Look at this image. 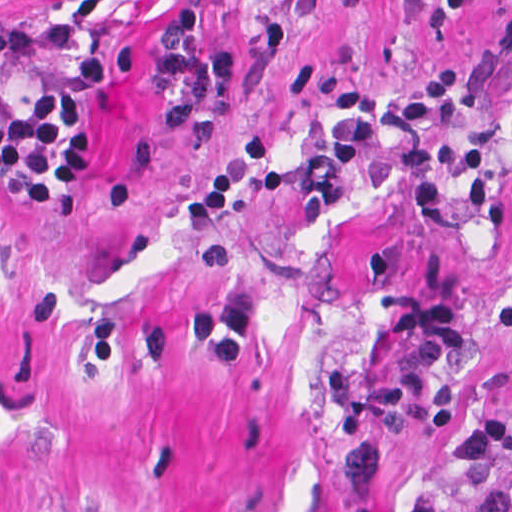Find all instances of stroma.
<instances>
[{"label": "stroma", "instance_id": "obj_1", "mask_svg": "<svg viewBox=\"0 0 512 512\" xmlns=\"http://www.w3.org/2000/svg\"><path fill=\"white\" fill-rule=\"evenodd\" d=\"M205 15L234 93L170 132L140 56L92 92L71 67ZM456 73L434 143L501 135L506 226L406 223L384 132L328 205L242 184L184 203L250 136L315 163L346 129L322 94L400 98ZM77 84L90 182L31 213L0 188V512H440L463 425L508 394L493 311L512 293V0H0V80Z\"/></svg>", "mask_w": 512, "mask_h": 512}]
</instances>
